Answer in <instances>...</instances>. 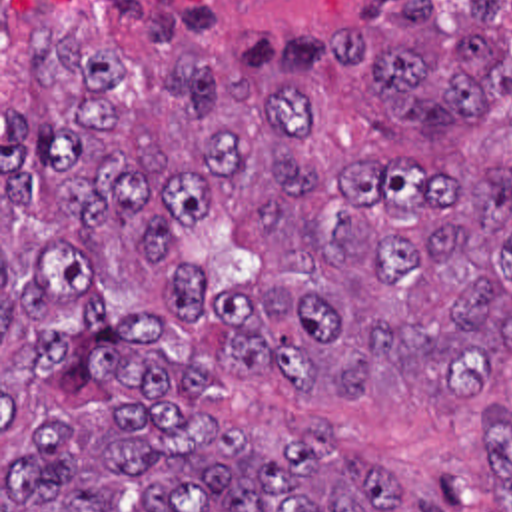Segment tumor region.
Wrapping results in <instances>:
<instances>
[{
    "mask_svg": "<svg viewBox=\"0 0 512 512\" xmlns=\"http://www.w3.org/2000/svg\"><path fill=\"white\" fill-rule=\"evenodd\" d=\"M335 54L373 74L393 122H477L512 88L495 44L443 28L435 0H357ZM28 70L78 82V98L52 128L2 108L4 208L34 206L46 176L62 222L118 228L178 310L204 294L180 228L246 222L270 270L216 298L236 322L228 370H266L311 410L443 404L479 422L512 372L511 170L447 180L405 160H343L305 84L246 86L202 60L156 58L146 96H112L114 54L68 32ZM58 304L84 308L80 330L28 336L8 354L16 376L52 394L118 384L160 404L102 402L18 428L2 512H443L313 424L262 447L240 424L186 412L212 374L162 354L160 318L106 320L92 270L68 250H44L22 280L2 260V330ZM485 432L512 512V406L491 408Z\"/></svg>",
    "mask_w": 512,
    "mask_h": 512,
    "instance_id": "e687c5a6",
    "label": "tumor region"
}]
</instances>
